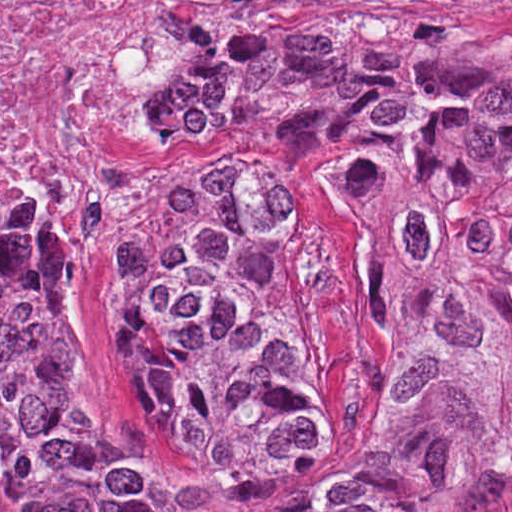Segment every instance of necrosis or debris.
I'll return each mask as SVG.
<instances>
[{"label":"necrosis or debris","instance_id":"4bbe7bcc","mask_svg":"<svg viewBox=\"0 0 512 512\" xmlns=\"http://www.w3.org/2000/svg\"><path fill=\"white\" fill-rule=\"evenodd\" d=\"M346 0H1V212L116 297L158 197L161 104L207 30Z\"/></svg>","mask_w":512,"mask_h":512}]
</instances>
